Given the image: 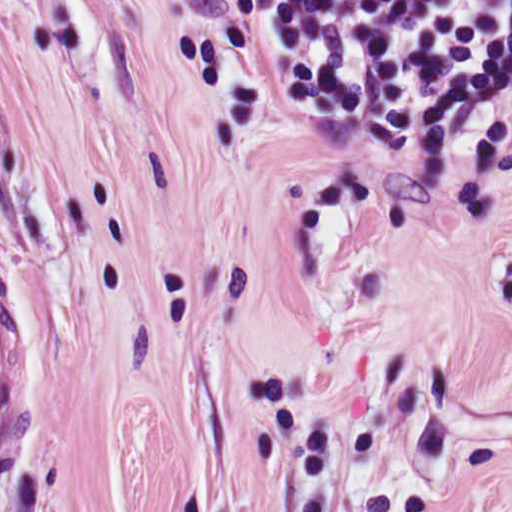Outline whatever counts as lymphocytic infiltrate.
I'll return each instance as SVG.
<instances>
[{"label": "lymphocytic infiltrate", "instance_id": "obj_1", "mask_svg": "<svg viewBox=\"0 0 512 512\" xmlns=\"http://www.w3.org/2000/svg\"><path fill=\"white\" fill-rule=\"evenodd\" d=\"M272 87L301 110L432 131L512 75V0H226Z\"/></svg>", "mask_w": 512, "mask_h": 512}]
</instances>
